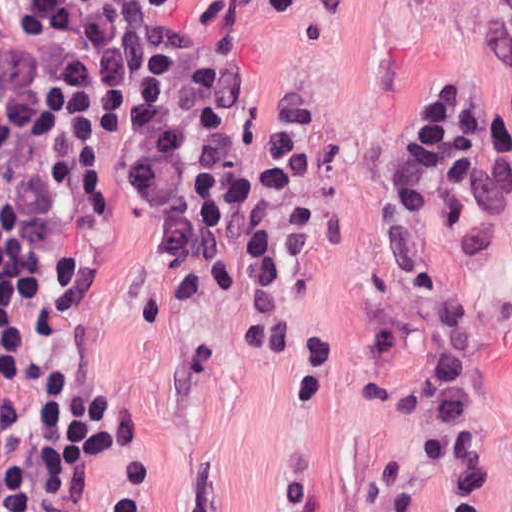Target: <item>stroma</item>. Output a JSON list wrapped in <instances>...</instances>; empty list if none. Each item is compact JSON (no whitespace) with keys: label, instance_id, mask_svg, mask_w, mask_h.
Segmentation results:
<instances>
[{"label":"stroma","instance_id":"obj_1","mask_svg":"<svg viewBox=\"0 0 512 512\" xmlns=\"http://www.w3.org/2000/svg\"><path fill=\"white\" fill-rule=\"evenodd\" d=\"M29 0H0V64ZM183 30L227 9L241 61L220 107L214 160L237 190L271 176L301 112L315 177L284 314L269 335L250 264L232 297L168 244L172 212L144 197L131 166L142 81L129 79L97 149L116 233L93 318L136 383L129 429L76 465L87 512H101L131 462L140 512L380 511L375 465L398 460L419 512H443L415 435L362 400L408 384L425 348L373 329L457 298L484 347L489 512H512V246L487 248L433 207L415 283L393 234L388 175L403 129L445 85L512 165V69L475 50L477 19L441 0H139ZM0 512H16L0 448Z\"/></svg>","mask_w":512,"mask_h":512}]
</instances>
